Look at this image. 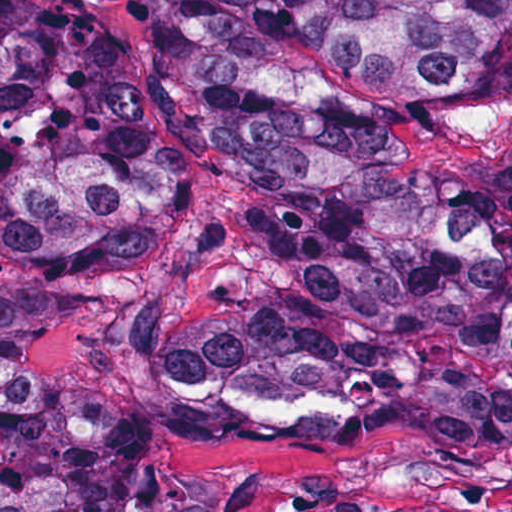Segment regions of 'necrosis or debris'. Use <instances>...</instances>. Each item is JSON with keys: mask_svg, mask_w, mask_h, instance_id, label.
Wrapping results in <instances>:
<instances>
[{"mask_svg": "<svg viewBox=\"0 0 512 512\" xmlns=\"http://www.w3.org/2000/svg\"><path fill=\"white\" fill-rule=\"evenodd\" d=\"M445 50L468 112L421 193L446 226L512 258V0H469ZM507 348L512 367V329Z\"/></svg>", "mask_w": 512, "mask_h": 512, "instance_id": "obj_1", "label": "necrosis or debris"}]
</instances>
